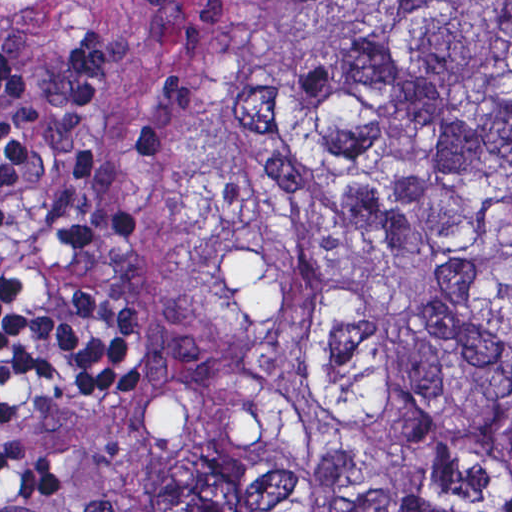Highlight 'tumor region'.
<instances>
[{"label": "tumor region", "mask_w": 512, "mask_h": 512, "mask_svg": "<svg viewBox=\"0 0 512 512\" xmlns=\"http://www.w3.org/2000/svg\"><path fill=\"white\" fill-rule=\"evenodd\" d=\"M173 392L127 512H434L512 477V1H293L142 115Z\"/></svg>", "instance_id": "1"}]
</instances>
